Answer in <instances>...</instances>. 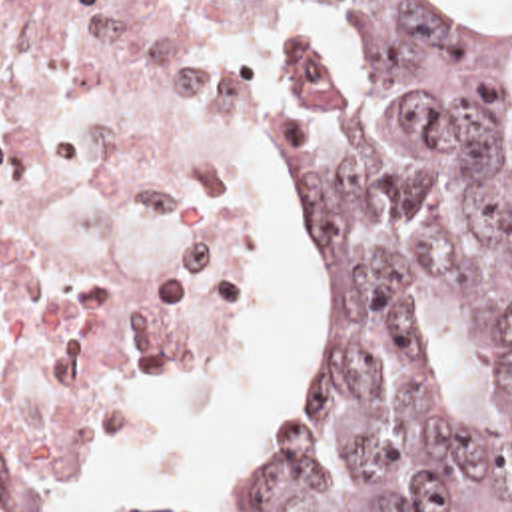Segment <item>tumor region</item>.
<instances>
[{"instance_id":"obj_1","label":"tumor region","mask_w":512,"mask_h":512,"mask_svg":"<svg viewBox=\"0 0 512 512\" xmlns=\"http://www.w3.org/2000/svg\"><path fill=\"white\" fill-rule=\"evenodd\" d=\"M331 1L380 105L277 23L271 231L303 309V408L239 464L241 508L512 512V37L440 0ZM468 285L508 364L500 440L422 352L420 303Z\"/></svg>"}]
</instances>
